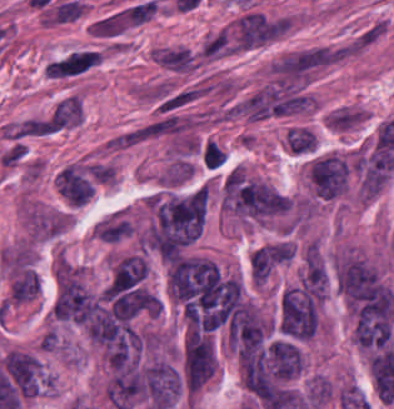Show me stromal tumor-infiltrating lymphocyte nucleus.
Instances as JSON below:
<instances>
[{
    "label": "stromal tumor-infiltrating lymphocyte nucleus",
    "mask_w": 394,
    "mask_h": 409,
    "mask_svg": "<svg viewBox=\"0 0 394 409\" xmlns=\"http://www.w3.org/2000/svg\"><path fill=\"white\" fill-rule=\"evenodd\" d=\"M225 153L215 140H207L202 148V159L210 168H219L223 164Z\"/></svg>",
    "instance_id": "stromal-tumor-infiltrating-lymphocyte-nucleus-1"
},
{
    "label": "stromal tumor-infiltrating lymphocyte nucleus",
    "mask_w": 394,
    "mask_h": 409,
    "mask_svg": "<svg viewBox=\"0 0 394 409\" xmlns=\"http://www.w3.org/2000/svg\"><path fill=\"white\" fill-rule=\"evenodd\" d=\"M216 366H217V357H216V348H215V344H214L211 379H212V377L214 375V372L216 370Z\"/></svg>",
    "instance_id": "stromal-tumor-infiltrating-lymphocyte-nucleus-2"
}]
</instances>
